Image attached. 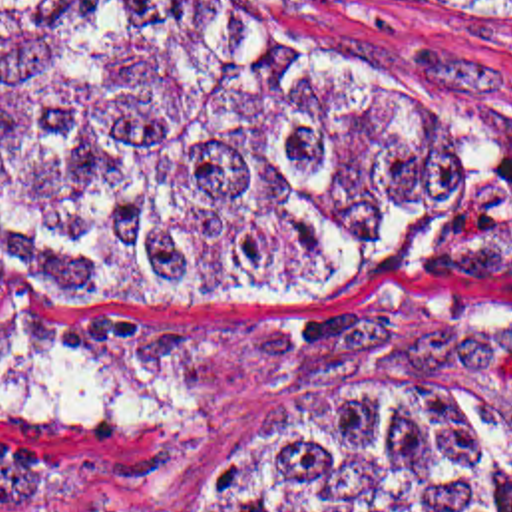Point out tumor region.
Here are the masks:
<instances>
[{"mask_svg": "<svg viewBox=\"0 0 512 512\" xmlns=\"http://www.w3.org/2000/svg\"><path fill=\"white\" fill-rule=\"evenodd\" d=\"M246 1L0 0V282L216 298L340 262L418 200L428 114ZM87 489L71 465H0V501ZM199 512H512V411L314 389L222 451Z\"/></svg>", "mask_w": 512, "mask_h": 512, "instance_id": "obj_1", "label": "tumor region"}]
</instances>
